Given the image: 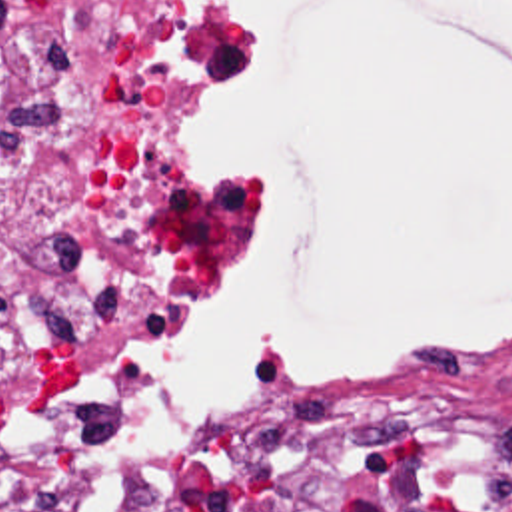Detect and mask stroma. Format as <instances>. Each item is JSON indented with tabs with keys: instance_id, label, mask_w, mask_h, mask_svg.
<instances>
[{
	"instance_id": "obj_1",
	"label": "stroma",
	"mask_w": 512,
	"mask_h": 512,
	"mask_svg": "<svg viewBox=\"0 0 512 512\" xmlns=\"http://www.w3.org/2000/svg\"><path fill=\"white\" fill-rule=\"evenodd\" d=\"M221 160L257 204L235 266L121 393L123 479L221 512L201 457L361 376L453 383L512 425V4L243 0Z\"/></svg>"
}]
</instances>
